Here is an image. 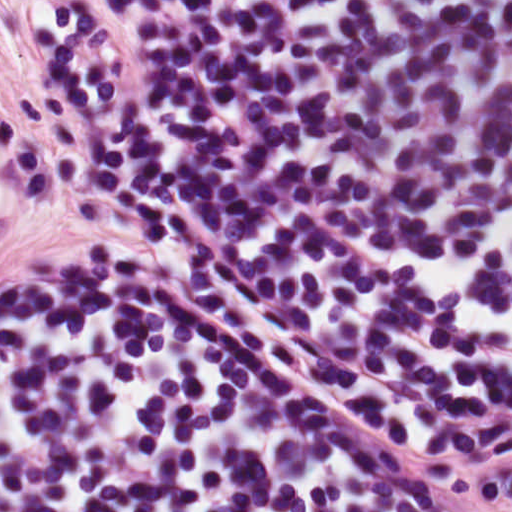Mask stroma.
Wrapping results in <instances>:
<instances>
[{
  "label": "stroma",
  "instance_id": "35a3bbf8",
  "mask_svg": "<svg viewBox=\"0 0 512 512\" xmlns=\"http://www.w3.org/2000/svg\"><path fill=\"white\" fill-rule=\"evenodd\" d=\"M0 117L21 160L0 226V292L51 261H117L1 0Z\"/></svg>",
  "mask_w": 512,
  "mask_h": 512
}]
</instances>
